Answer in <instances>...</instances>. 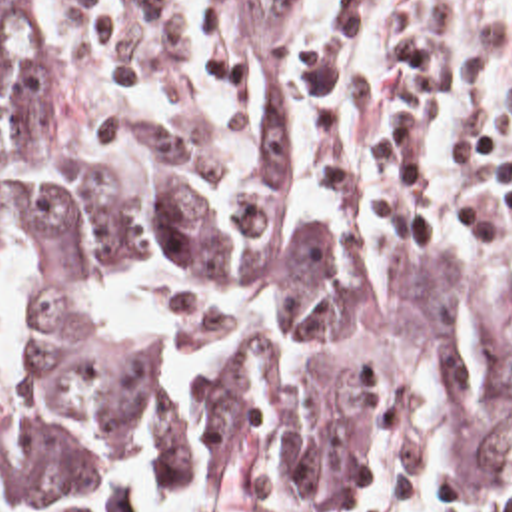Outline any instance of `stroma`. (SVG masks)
<instances>
[{
    "label": "stroma",
    "mask_w": 512,
    "mask_h": 512,
    "mask_svg": "<svg viewBox=\"0 0 512 512\" xmlns=\"http://www.w3.org/2000/svg\"><path fill=\"white\" fill-rule=\"evenodd\" d=\"M79 79L101 109L175 115L231 143L241 135L239 13L235 0H67ZM291 179L313 217L403 241L443 271L512 297V271L413 235L377 231L315 189L309 159V35L293 57ZM453 387L419 381L379 397L369 470L359 498L295 508L265 496H221V512H435L497 490L463 480L449 442Z\"/></svg>",
    "instance_id": "obj_1"
}]
</instances>
